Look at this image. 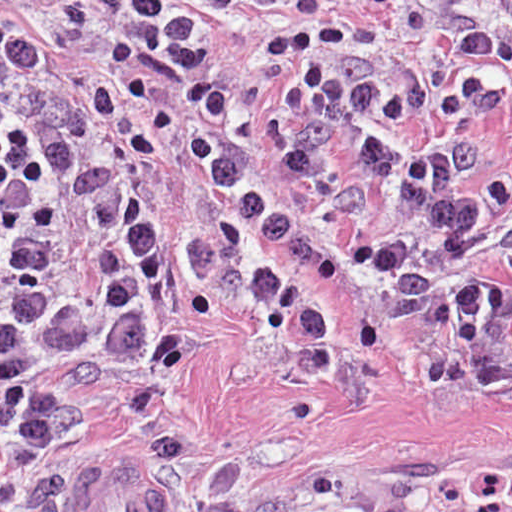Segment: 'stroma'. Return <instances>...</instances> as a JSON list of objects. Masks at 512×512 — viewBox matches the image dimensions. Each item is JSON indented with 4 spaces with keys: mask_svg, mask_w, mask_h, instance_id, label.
<instances>
[{
    "mask_svg": "<svg viewBox=\"0 0 512 512\" xmlns=\"http://www.w3.org/2000/svg\"><path fill=\"white\" fill-rule=\"evenodd\" d=\"M177 1L214 46L199 72L216 96L270 94L296 55L271 59L268 41L325 28L389 58L483 74L464 105L407 122L393 140L405 154L456 141L479 161L464 184L488 243L475 276L512 286V0ZM122 25L111 11L74 23L63 0H0V73L63 75L80 146L131 184L153 132L129 105L101 117L91 96L118 74ZM151 88L178 115L189 108L157 79ZM0 326H18L3 279ZM100 371L116 411L74 434L68 467L0 470V512L81 502L512 512V374L401 318L357 280L327 299L254 275L177 271L149 298L133 346Z\"/></svg>",
    "mask_w": 512,
    "mask_h": 512,
    "instance_id": "stroma-1",
    "label": "stroma"
}]
</instances>
